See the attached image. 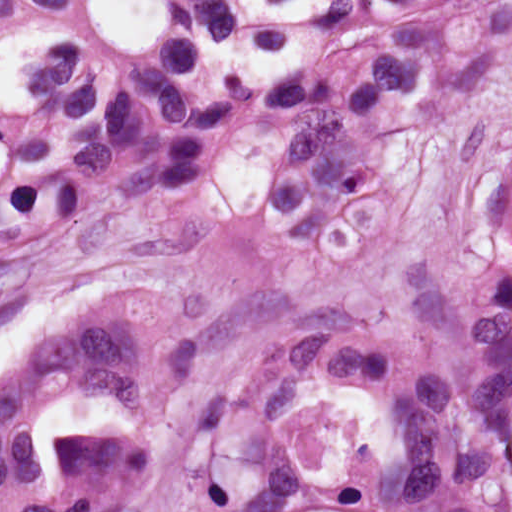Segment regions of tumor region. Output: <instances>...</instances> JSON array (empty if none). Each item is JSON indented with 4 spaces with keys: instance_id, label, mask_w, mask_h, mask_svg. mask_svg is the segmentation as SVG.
<instances>
[{
    "instance_id": "e687c5a6",
    "label": "tumor region",
    "mask_w": 512,
    "mask_h": 512,
    "mask_svg": "<svg viewBox=\"0 0 512 512\" xmlns=\"http://www.w3.org/2000/svg\"><path fill=\"white\" fill-rule=\"evenodd\" d=\"M512 69V4L266 114L294 136L260 191L277 247L304 263L373 254L402 207L393 116L431 79L448 97ZM223 134L112 183L136 200L213 171ZM402 351L315 339L196 440L133 512H498L512 466V159L479 197L453 261H405ZM74 400L112 395L141 420L202 364L181 295H123L46 336ZM124 512L147 483L127 434H90Z\"/></svg>"
}]
</instances>
